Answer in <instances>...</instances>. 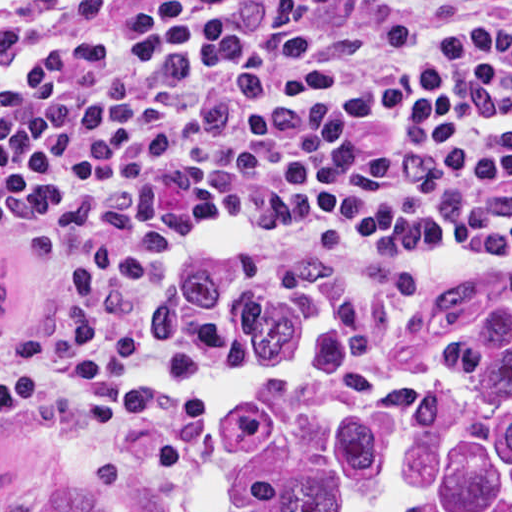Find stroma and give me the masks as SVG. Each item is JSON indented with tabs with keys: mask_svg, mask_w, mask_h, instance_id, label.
<instances>
[{
	"mask_svg": "<svg viewBox=\"0 0 512 512\" xmlns=\"http://www.w3.org/2000/svg\"><path fill=\"white\" fill-rule=\"evenodd\" d=\"M67 0L55 5H23L0 18V54L17 45ZM374 263H411L441 271L495 269L512 266V229L483 235H429L404 242L354 249H289L245 252L221 269L244 275L274 267H357ZM97 380V379H96ZM18 406L0 416L53 406L77 390Z\"/></svg>",
	"mask_w": 512,
	"mask_h": 512,
	"instance_id": "35a3bbf8",
	"label": "stroma"
}]
</instances>
